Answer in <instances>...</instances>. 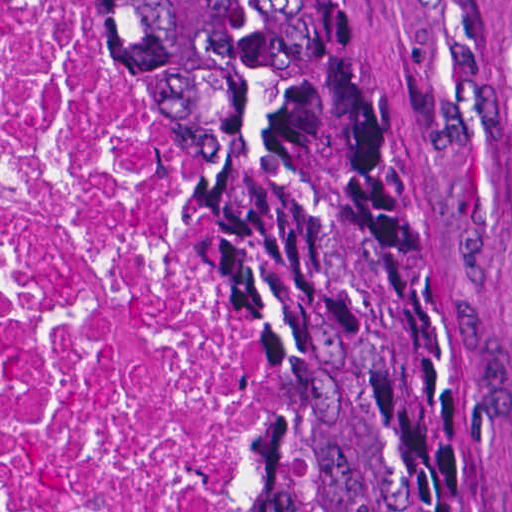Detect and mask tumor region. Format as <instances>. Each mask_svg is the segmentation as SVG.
<instances>
[{
  "label": "tumor region",
  "mask_w": 512,
  "mask_h": 512,
  "mask_svg": "<svg viewBox=\"0 0 512 512\" xmlns=\"http://www.w3.org/2000/svg\"><path fill=\"white\" fill-rule=\"evenodd\" d=\"M260 287L245 512H481L454 295L363 0H110Z\"/></svg>",
  "instance_id": "obj_1"
}]
</instances>
